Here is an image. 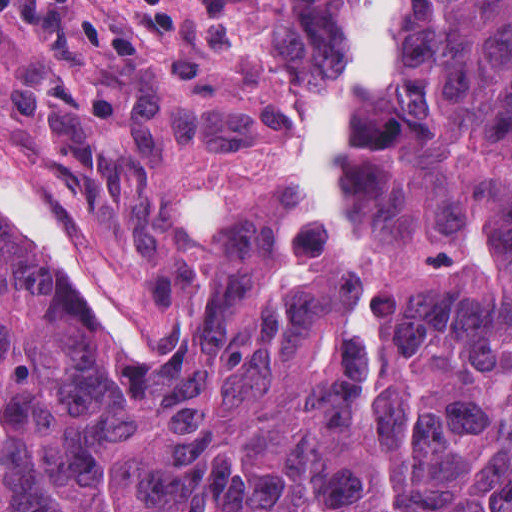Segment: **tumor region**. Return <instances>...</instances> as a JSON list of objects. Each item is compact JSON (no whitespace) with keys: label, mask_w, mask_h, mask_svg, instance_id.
Returning <instances> with one entry per match:
<instances>
[{"label":"tumor region","mask_w":512,"mask_h":512,"mask_svg":"<svg viewBox=\"0 0 512 512\" xmlns=\"http://www.w3.org/2000/svg\"><path fill=\"white\" fill-rule=\"evenodd\" d=\"M154 364L121 271L0 183V512H512V0H425L342 144Z\"/></svg>","instance_id":"1"}]
</instances>
